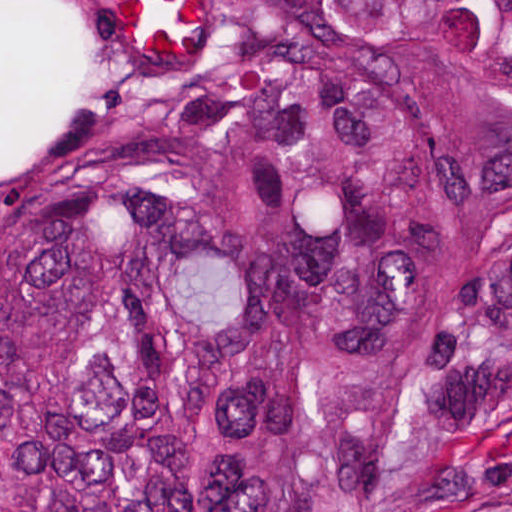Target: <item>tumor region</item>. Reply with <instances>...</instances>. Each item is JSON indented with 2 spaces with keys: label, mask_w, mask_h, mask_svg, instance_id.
<instances>
[{
  "label": "tumor region",
  "mask_w": 512,
  "mask_h": 512,
  "mask_svg": "<svg viewBox=\"0 0 512 512\" xmlns=\"http://www.w3.org/2000/svg\"><path fill=\"white\" fill-rule=\"evenodd\" d=\"M0 512H512V0H0Z\"/></svg>",
  "instance_id": "1"
}]
</instances>
